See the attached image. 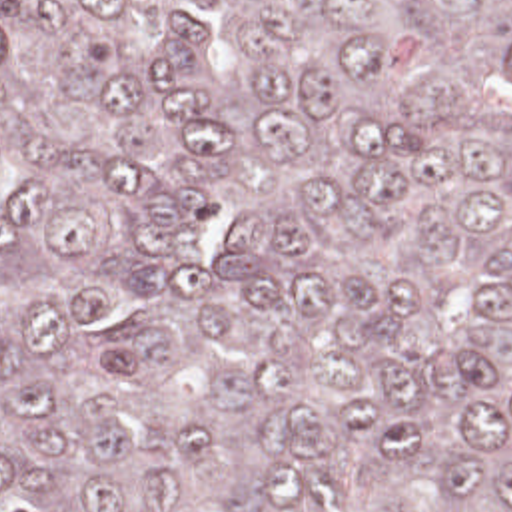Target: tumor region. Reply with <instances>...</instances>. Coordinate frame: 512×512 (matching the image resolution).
Here are the masks:
<instances>
[{"mask_svg":"<svg viewBox=\"0 0 512 512\" xmlns=\"http://www.w3.org/2000/svg\"><path fill=\"white\" fill-rule=\"evenodd\" d=\"M0 512H512V0H0Z\"/></svg>","mask_w":512,"mask_h":512,"instance_id":"e687c5a6","label":"tumor region"}]
</instances>
